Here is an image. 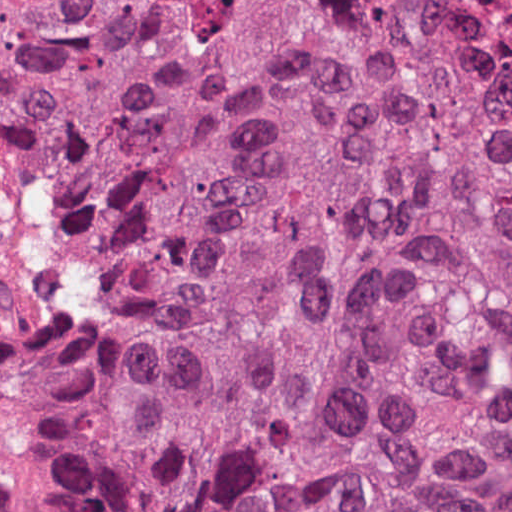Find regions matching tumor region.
<instances>
[{"label": "tumor region", "instance_id": "e687c5a6", "mask_svg": "<svg viewBox=\"0 0 512 512\" xmlns=\"http://www.w3.org/2000/svg\"><path fill=\"white\" fill-rule=\"evenodd\" d=\"M0 443L50 512H512V0H0Z\"/></svg>", "mask_w": 512, "mask_h": 512}]
</instances>
